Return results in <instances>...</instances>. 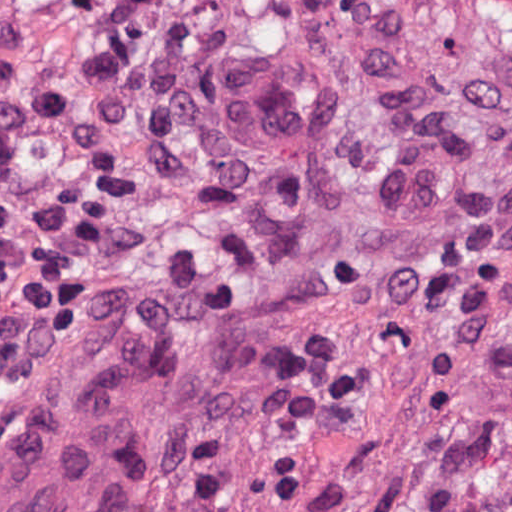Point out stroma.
I'll return each instance as SVG.
<instances>
[{"label": "stroma", "mask_w": 512, "mask_h": 512, "mask_svg": "<svg viewBox=\"0 0 512 512\" xmlns=\"http://www.w3.org/2000/svg\"><path fill=\"white\" fill-rule=\"evenodd\" d=\"M404 1L478 44L464 91L401 145L316 72L232 64L213 203L76 271L0 382V512H512V0Z\"/></svg>", "instance_id": "35a3bbf8"}]
</instances>
